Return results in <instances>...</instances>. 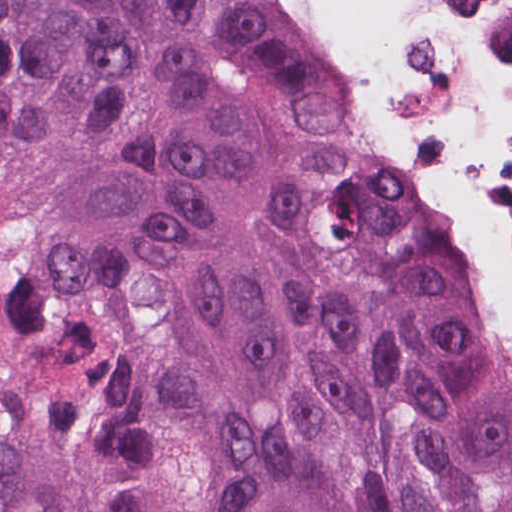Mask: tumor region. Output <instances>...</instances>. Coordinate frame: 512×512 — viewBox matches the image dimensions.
<instances>
[{
    "instance_id": "e687c5a6",
    "label": "tumor region",
    "mask_w": 512,
    "mask_h": 512,
    "mask_svg": "<svg viewBox=\"0 0 512 512\" xmlns=\"http://www.w3.org/2000/svg\"><path fill=\"white\" fill-rule=\"evenodd\" d=\"M0 512H512V343L277 0H0Z\"/></svg>"
}]
</instances>
